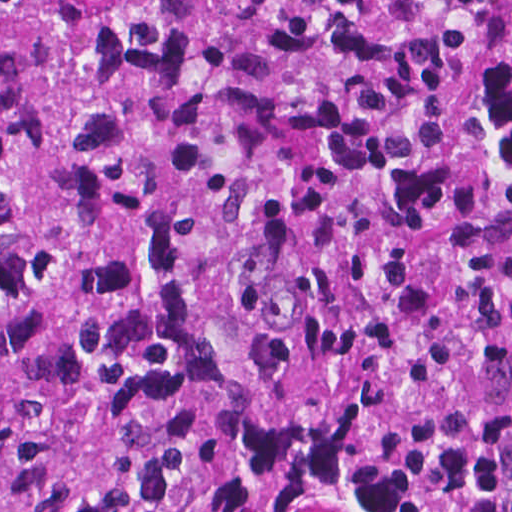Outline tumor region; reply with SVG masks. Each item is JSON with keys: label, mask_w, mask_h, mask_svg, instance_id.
Here are the masks:
<instances>
[{"label": "tumor region", "mask_w": 512, "mask_h": 512, "mask_svg": "<svg viewBox=\"0 0 512 512\" xmlns=\"http://www.w3.org/2000/svg\"><path fill=\"white\" fill-rule=\"evenodd\" d=\"M0 512H512V0H0Z\"/></svg>", "instance_id": "tumor-region-1"}]
</instances>
